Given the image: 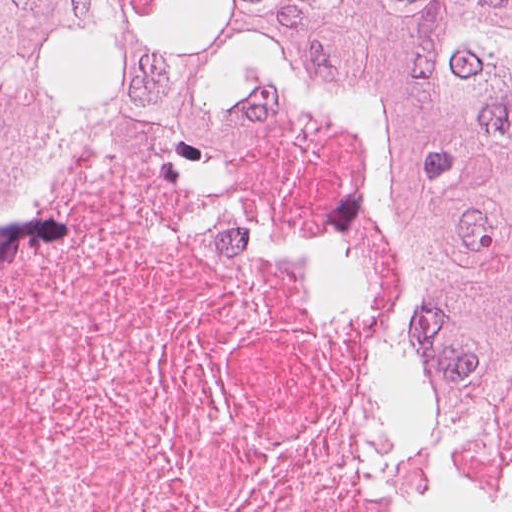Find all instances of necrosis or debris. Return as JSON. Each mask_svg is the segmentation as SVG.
I'll return each mask as SVG.
<instances>
[{
  "instance_id": "necrosis-or-debris-1",
  "label": "necrosis or debris",
  "mask_w": 512,
  "mask_h": 512,
  "mask_svg": "<svg viewBox=\"0 0 512 512\" xmlns=\"http://www.w3.org/2000/svg\"><path fill=\"white\" fill-rule=\"evenodd\" d=\"M408 179L348 93L67 83L0 158V512H512L419 437Z\"/></svg>"
}]
</instances>
